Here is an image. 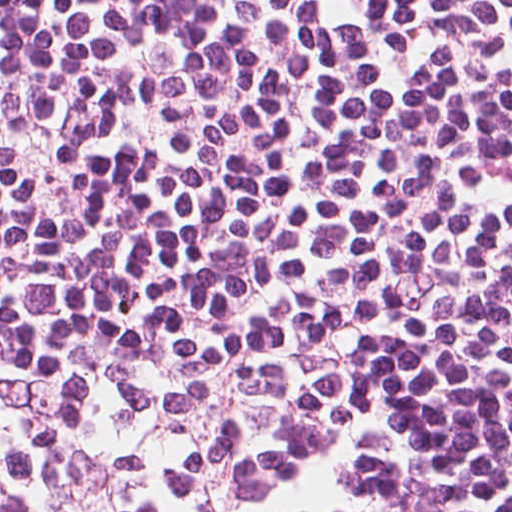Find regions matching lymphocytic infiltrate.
<instances>
[{
  "mask_svg": "<svg viewBox=\"0 0 512 512\" xmlns=\"http://www.w3.org/2000/svg\"><path fill=\"white\" fill-rule=\"evenodd\" d=\"M0 512H512V0H0Z\"/></svg>",
  "mask_w": 512,
  "mask_h": 512,
  "instance_id": "f902f5d3",
  "label": "lymphocytic infiltrate"
}]
</instances>
